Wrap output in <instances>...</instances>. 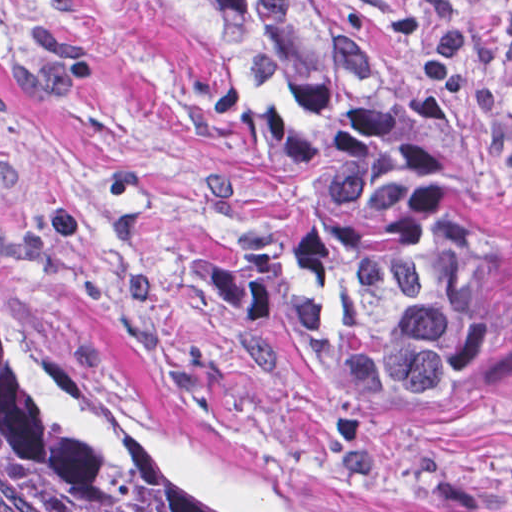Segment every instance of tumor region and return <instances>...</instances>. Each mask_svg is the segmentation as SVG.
<instances>
[{"instance_id": "obj_1", "label": "tumor region", "mask_w": 512, "mask_h": 512, "mask_svg": "<svg viewBox=\"0 0 512 512\" xmlns=\"http://www.w3.org/2000/svg\"><path fill=\"white\" fill-rule=\"evenodd\" d=\"M208 1L244 53L217 123L278 164L312 221L280 299L306 352L402 435L497 393L512 269L473 229L423 111L323 0ZM0 491L18 512H215L46 377L1 265Z\"/></svg>"}]
</instances>
